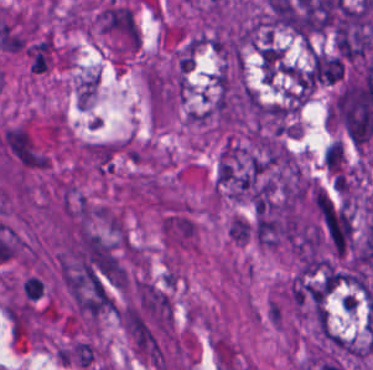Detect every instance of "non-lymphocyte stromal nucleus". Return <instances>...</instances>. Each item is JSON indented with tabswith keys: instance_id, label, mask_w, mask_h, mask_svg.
<instances>
[{
	"instance_id": "non-lymphocyte-stromal-nucleus-2",
	"label": "non-lymphocyte stromal nucleus",
	"mask_w": 373,
	"mask_h": 370,
	"mask_svg": "<svg viewBox=\"0 0 373 370\" xmlns=\"http://www.w3.org/2000/svg\"><path fill=\"white\" fill-rule=\"evenodd\" d=\"M253 235V223L246 218L233 216L229 237L238 245H246Z\"/></svg>"
},
{
	"instance_id": "non-lymphocyte-stromal-nucleus-1",
	"label": "non-lymphocyte stromal nucleus",
	"mask_w": 373,
	"mask_h": 370,
	"mask_svg": "<svg viewBox=\"0 0 373 370\" xmlns=\"http://www.w3.org/2000/svg\"><path fill=\"white\" fill-rule=\"evenodd\" d=\"M197 226L187 214L173 212L162 220V233L168 244L175 246L193 245Z\"/></svg>"
}]
</instances>
